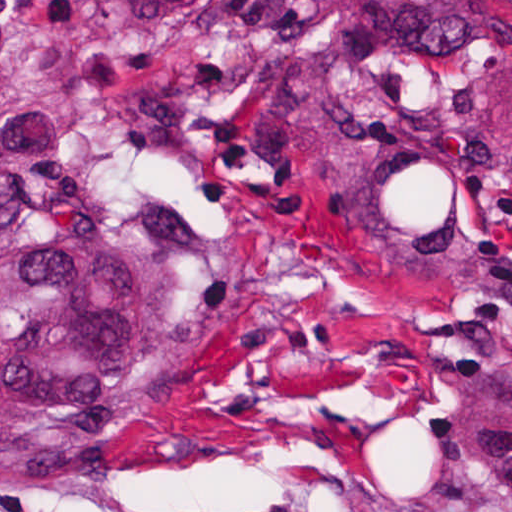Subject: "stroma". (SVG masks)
I'll use <instances>...</instances> for the list:
<instances>
[{
  "label": "stroma",
  "instance_id": "1",
  "mask_svg": "<svg viewBox=\"0 0 512 512\" xmlns=\"http://www.w3.org/2000/svg\"><path fill=\"white\" fill-rule=\"evenodd\" d=\"M512 223V112L462 108ZM165 203L294 293L117 461L0 477V512H512V302L394 268L353 230L234 190L155 118Z\"/></svg>",
  "mask_w": 512,
  "mask_h": 512
}]
</instances>
